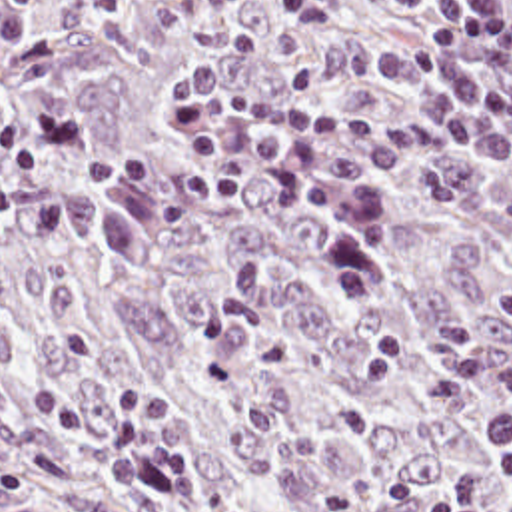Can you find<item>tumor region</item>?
I'll return each mask as SVG.
<instances>
[{
	"mask_svg": "<svg viewBox=\"0 0 512 512\" xmlns=\"http://www.w3.org/2000/svg\"><path fill=\"white\" fill-rule=\"evenodd\" d=\"M439 2L50 0L0 40V512H431L465 473L511 505L477 431L512 408V172L431 138L375 64ZM199 58L363 130L321 150L373 184L359 306L271 126L235 120L239 198L183 196Z\"/></svg>",
	"mask_w": 512,
	"mask_h": 512,
	"instance_id": "tumor-region-1",
	"label": "tumor region"
}]
</instances>
